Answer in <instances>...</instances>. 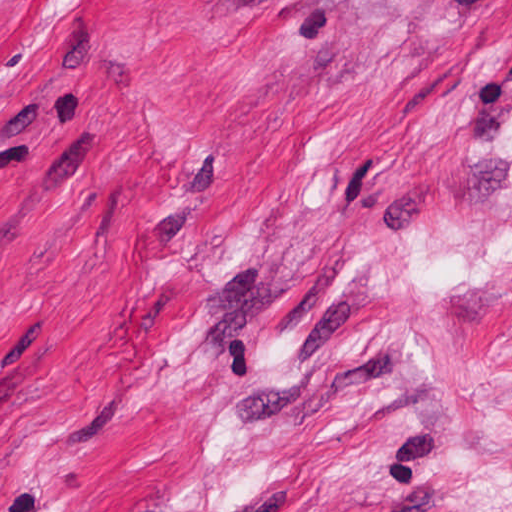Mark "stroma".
Instances as JSON below:
<instances>
[{
  "mask_svg": "<svg viewBox=\"0 0 512 512\" xmlns=\"http://www.w3.org/2000/svg\"><path fill=\"white\" fill-rule=\"evenodd\" d=\"M0 512H512V0H0Z\"/></svg>",
  "mask_w": 512,
  "mask_h": 512,
  "instance_id": "obj_1",
  "label": "stroma"
}]
</instances>
